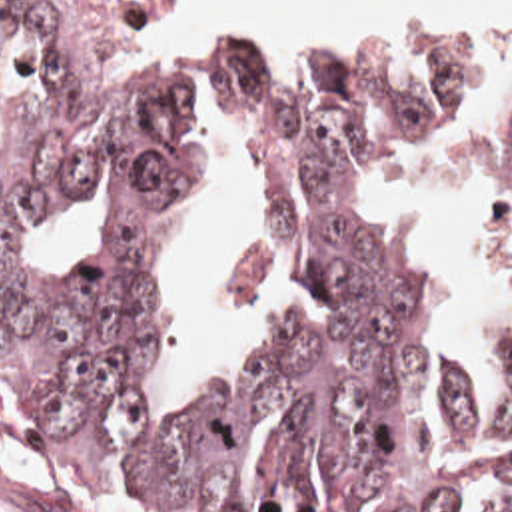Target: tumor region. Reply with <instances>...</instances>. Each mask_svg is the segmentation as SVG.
Returning a JSON list of instances; mask_svg holds the SVG:
<instances>
[{
  "label": "tumor region",
  "instance_id": "obj_1",
  "mask_svg": "<svg viewBox=\"0 0 512 512\" xmlns=\"http://www.w3.org/2000/svg\"><path fill=\"white\" fill-rule=\"evenodd\" d=\"M39 80L0 152V434L178 512H462L480 489L472 396L434 348L416 286L364 234L358 184L466 98L476 64L438 36L336 58L206 62L272 186L274 332L186 414H144L154 250L184 214L194 152L152 82L111 80L53 0H0ZM111 164L107 232L29 272L25 226ZM482 214L512 226V90L480 170ZM466 512H512V464Z\"/></svg>",
  "mask_w": 512,
  "mask_h": 512
}]
</instances>
